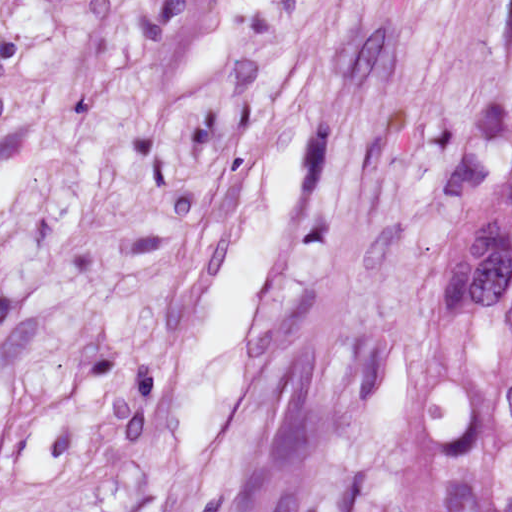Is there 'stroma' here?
Instances as JSON below:
<instances>
[{"label":"stroma","instance_id":"stroma-1","mask_svg":"<svg viewBox=\"0 0 512 512\" xmlns=\"http://www.w3.org/2000/svg\"><path fill=\"white\" fill-rule=\"evenodd\" d=\"M512 0H0V512H431L451 128ZM289 135L294 227L205 456L188 339Z\"/></svg>","mask_w":512,"mask_h":512}]
</instances>
